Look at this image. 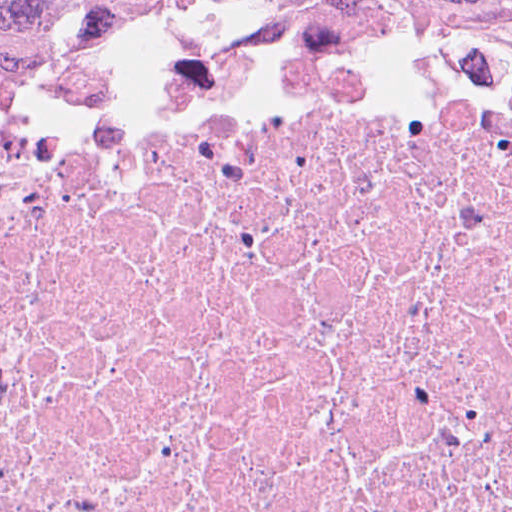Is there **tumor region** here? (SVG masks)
Listing matches in <instances>:
<instances>
[{
  "instance_id": "tumor-region-1",
  "label": "tumor region",
  "mask_w": 512,
  "mask_h": 512,
  "mask_svg": "<svg viewBox=\"0 0 512 512\" xmlns=\"http://www.w3.org/2000/svg\"><path fill=\"white\" fill-rule=\"evenodd\" d=\"M261 8H347L413 34L512 41V0H0V91L168 25Z\"/></svg>"
}]
</instances>
